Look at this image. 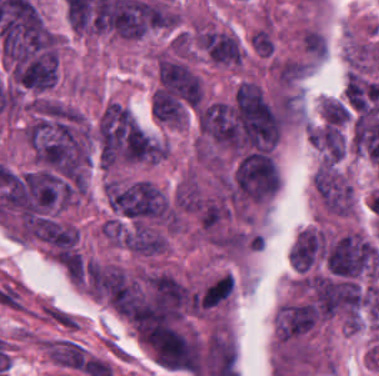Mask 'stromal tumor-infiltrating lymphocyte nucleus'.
Listing matches in <instances>:
<instances>
[{
    "label": "stromal tumor-infiltrating lymphocyte nucleus",
    "mask_w": 379,
    "mask_h": 376,
    "mask_svg": "<svg viewBox=\"0 0 379 376\" xmlns=\"http://www.w3.org/2000/svg\"><path fill=\"white\" fill-rule=\"evenodd\" d=\"M282 306H286L289 308H293L296 310H300V311L307 312V313L314 314V315L318 316V311H317L315 305H313V304L312 305H282Z\"/></svg>",
    "instance_id": "obj_1"
}]
</instances>
